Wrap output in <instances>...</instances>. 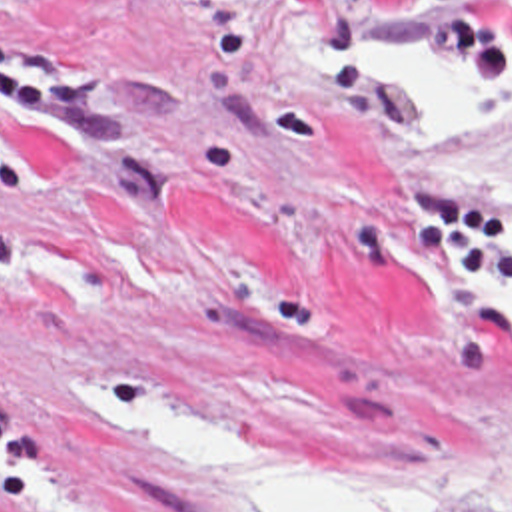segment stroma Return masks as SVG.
<instances>
[{
  "mask_svg": "<svg viewBox=\"0 0 512 512\" xmlns=\"http://www.w3.org/2000/svg\"><path fill=\"white\" fill-rule=\"evenodd\" d=\"M374 29L468 40L488 104L406 118L314 72ZM512 0H0V512H234L76 380L284 472L512 512Z\"/></svg>",
  "mask_w": 512,
  "mask_h": 512,
  "instance_id": "1",
  "label": "stroma"
}]
</instances>
